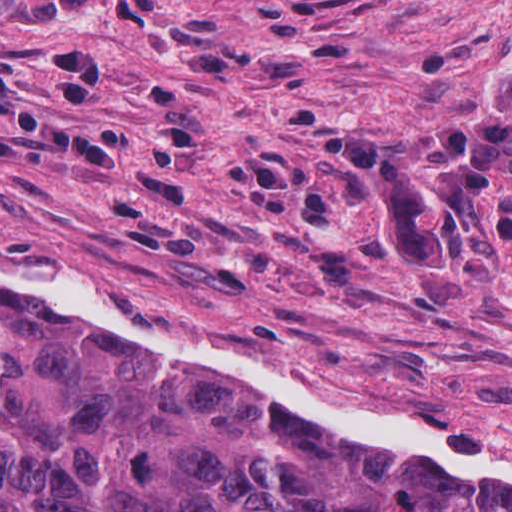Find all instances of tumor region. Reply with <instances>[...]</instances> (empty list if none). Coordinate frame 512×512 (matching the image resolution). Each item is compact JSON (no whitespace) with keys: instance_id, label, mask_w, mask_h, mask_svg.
Listing matches in <instances>:
<instances>
[{"instance_id":"obj_1","label":"tumor region","mask_w":512,"mask_h":512,"mask_svg":"<svg viewBox=\"0 0 512 512\" xmlns=\"http://www.w3.org/2000/svg\"><path fill=\"white\" fill-rule=\"evenodd\" d=\"M470 128L512 159V70ZM0 512H512V491L298 438L182 363L0 303Z\"/></svg>"}]
</instances>
